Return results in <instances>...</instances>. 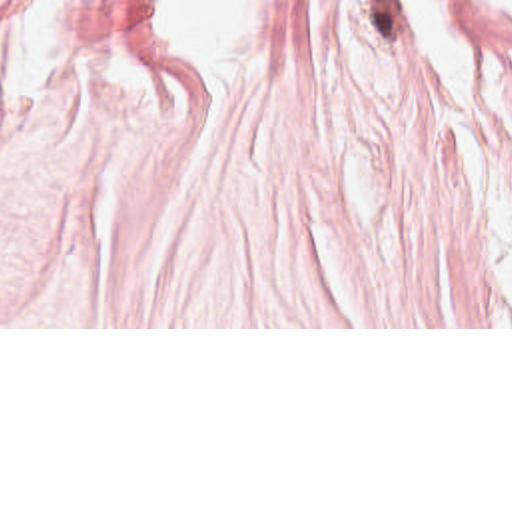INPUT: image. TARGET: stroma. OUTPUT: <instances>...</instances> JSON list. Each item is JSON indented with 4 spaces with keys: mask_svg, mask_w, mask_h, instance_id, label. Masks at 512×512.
I'll return each instance as SVG.
<instances>
[{
    "mask_svg": "<svg viewBox=\"0 0 512 512\" xmlns=\"http://www.w3.org/2000/svg\"><path fill=\"white\" fill-rule=\"evenodd\" d=\"M0 329H512V14L434 83L400 0H282L196 81L154 0H0Z\"/></svg>",
    "mask_w": 512,
    "mask_h": 512,
    "instance_id": "stroma-1",
    "label": "stroma"
}]
</instances>
